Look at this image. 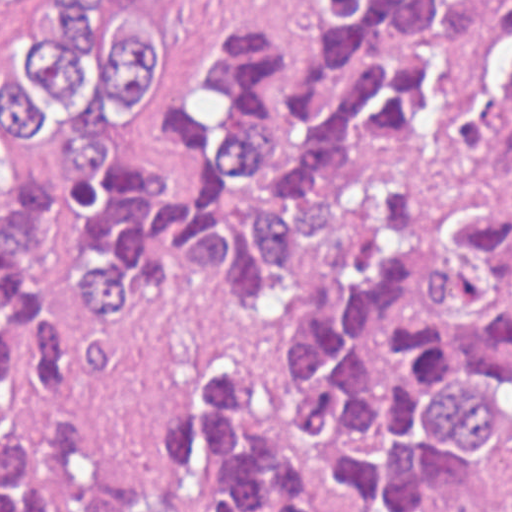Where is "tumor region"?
I'll return each instance as SVG.
<instances>
[{
  "mask_svg": "<svg viewBox=\"0 0 512 512\" xmlns=\"http://www.w3.org/2000/svg\"><path fill=\"white\" fill-rule=\"evenodd\" d=\"M512 0L247 17L163 113L164 0H1V512H498L512 443ZM442 48L437 138L417 55Z\"/></svg>",
  "mask_w": 512,
  "mask_h": 512,
  "instance_id": "obj_1",
  "label": "tumor region"
}]
</instances>
